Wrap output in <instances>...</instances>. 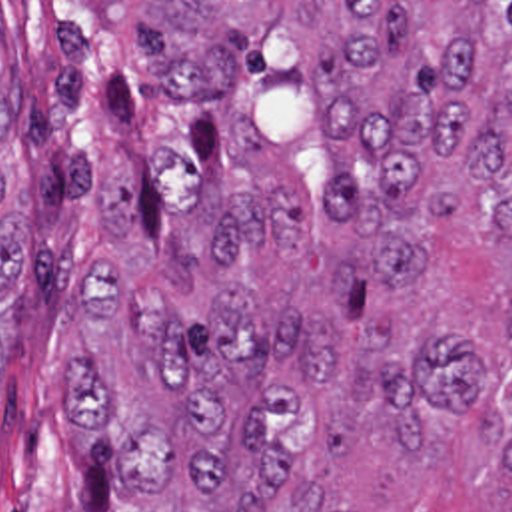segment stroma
I'll list each match as a JSON object with an SVG mask.
<instances>
[{"mask_svg": "<svg viewBox=\"0 0 512 512\" xmlns=\"http://www.w3.org/2000/svg\"><path fill=\"white\" fill-rule=\"evenodd\" d=\"M141 2H512V0H0V76L13 66L21 196L33 214L25 287L1 311L0 512H131L65 427L77 293L95 252L161 248L219 158L197 104L171 102L143 72ZM512 238L465 216L429 226L425 270L363 299L379 329L445 319L479 339L487 383L467 413H431L427 457L355 437L325 475L355 512H512V471L481 417L512 421Z\"/></svg>", "mask_w": 512, "mask_h": 512, "instance_id": "1", "label": "stroma"}]
</instances>
